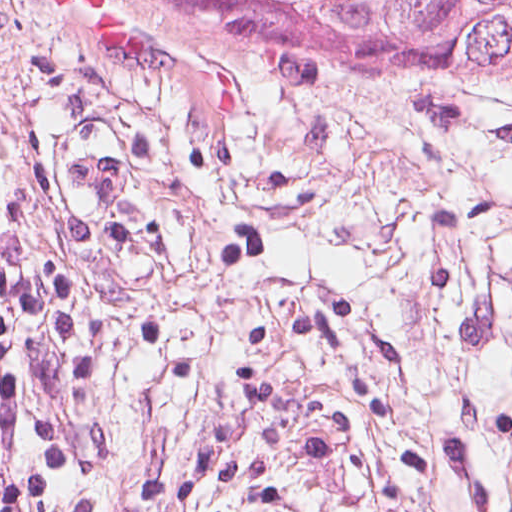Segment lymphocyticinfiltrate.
<instances>
[{"instance_id": "1", "label": "lymphocytic infiltrate", "mask_w": 512, "mask_h": 512, "mask_svg": "<svg viewBox=\"0 0 512 512\" xmlns=\"http://www.w3.org/2000/svg\"><path fill=\"white\" fill-rule=\"evenodd\" d=\"M0 512H71L58 487L41 414L1 306Z\"/></svg>"}]
</instances>
